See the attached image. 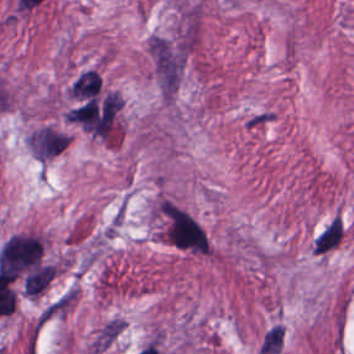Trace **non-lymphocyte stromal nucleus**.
<instances>
[{"label": "non-lymphocyte stromal nucleus", "mask_w": 354, "mask_h": 354, "mask_svg": "<svg viewBox=\"0 0 354 354\" xmlns=\"http://www.w3.org/2000/svg\"><path fill=\"white\" fill-rule=\"evenodd\" d=\"M153 58L163 91L173 92L179 80V56L166 40L156 36Z\"/></svg>", "instance_id": "obj_1"}]
</instances>
